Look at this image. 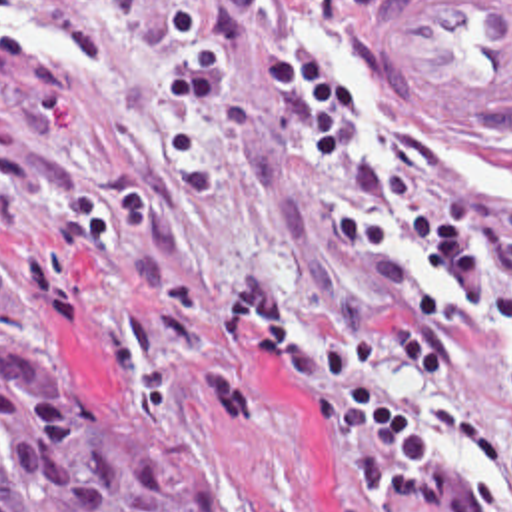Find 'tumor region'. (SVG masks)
Here are the masks:
<instances>
[{"label":"tumor region","instance_id":"1","mask_svg":"<svg viewBox=\"0 0 512 512\" xmlns=\"http://www.w3.org/2000/svg\"><path fill=\"white\" fill-rule=\"evenodd\" d=\"M0 512H244L216 467L92 371L0 351Z\"/></svg>","mask_w":512,"mask_h":512}]
</instances>
